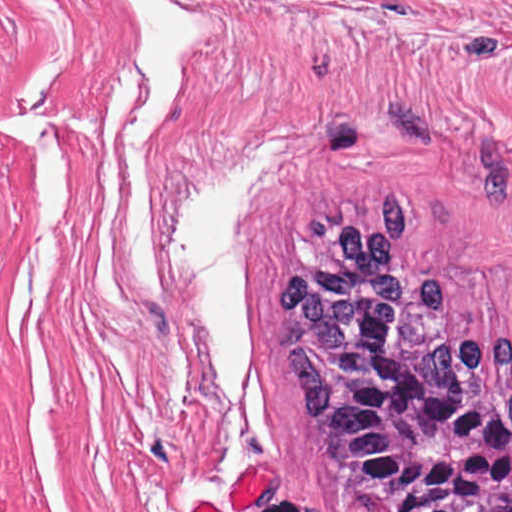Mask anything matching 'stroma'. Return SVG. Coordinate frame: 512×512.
<instances>
[{"mask_svg": "<svg viewBox=\"0 0 512 512\" xmlns=\"http://www.w3.org/2000/svg\"><path fill=\"white\" fill-rule=\"evenodd\" d=\"M195 27L146 145L155 287L133 295L114 97L135 12L90 0L36 512H372L340 487L272 337L283 230L359 189L411 199L400 251L467 335H512V0H165ZM283 140L244 245L241 396L205 376L175 207Z\"/></svg>", "mask_w": 512, "mask_h": 512, "instance_id": "stroma-1", "label": "stroma"}]
</instances>
